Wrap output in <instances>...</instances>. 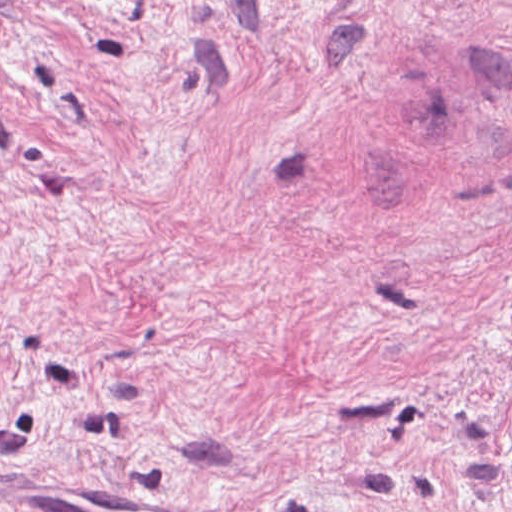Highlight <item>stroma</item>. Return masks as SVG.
<instances>
[{
    "label": "stroma",
    "mask_w": 512,
    "mask_h": 512,
    "mask_svg": "<svg viewBox=\"0 0 512 512\" xmlns=\"http://www.w3.org/2000/svg\"><path fill=\"white\" fill-rule=\"evenodd\" d=\"M0 512H512V0H0Z\"/></svg>",
    "instance_id": "obj_1"
}]
</instances>
